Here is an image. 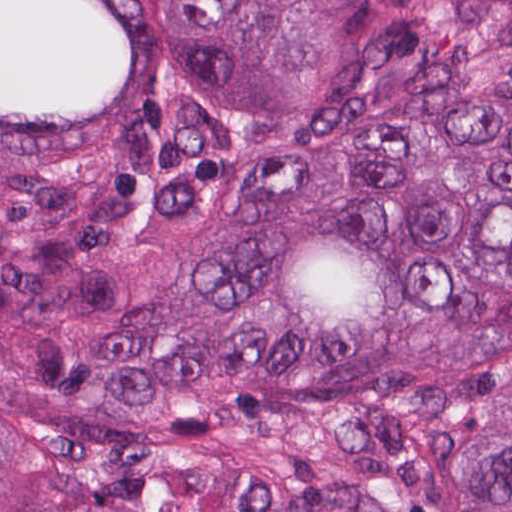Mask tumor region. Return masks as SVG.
<instances>
[{
	"label": "tumor region",
	"mask_w": 512,
	"mask_h": 512,
	"mask_svg": "<svg viewBox=\"0 0 512 512\" xmlns=\"http://www.w3.org/2000/svg\"><path fill=\"white\" fill-rule=\"evenodd\" d=\"M0 512H512V0H0Z\"/></svg>",
	"instance_id": "obj_1"
}]
</instances>
